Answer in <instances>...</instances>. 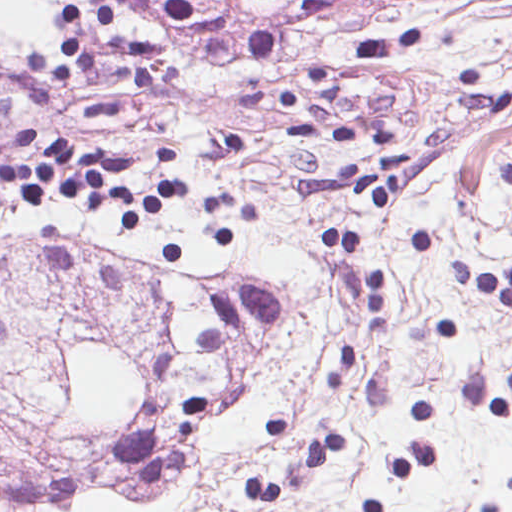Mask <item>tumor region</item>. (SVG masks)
<instances>
[{
  "label": "tumor region",
  "instance_id": "obj_1",
  "mask_svg": "<svg viewBox=\"0 0 512 512\" xmlns=\"http://www.w3.org/2000/svg\"><path fill=\"white\" fill-rule=\"evenodd\" d=\"M156 14L214 33H249L259 19L294 0H141Z\"/></svg>",
  "mask_w": 512,
  "mask_h": 512
}]
</instances>
